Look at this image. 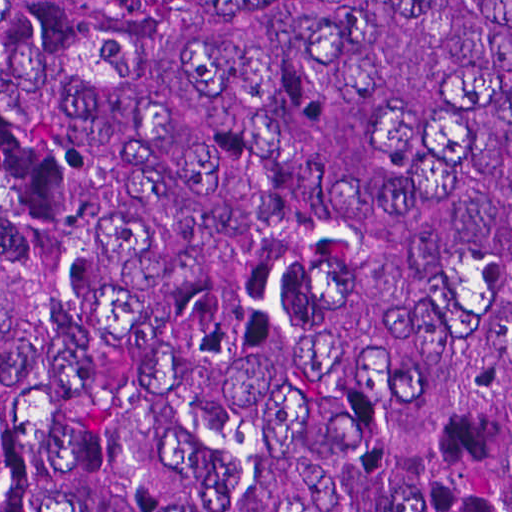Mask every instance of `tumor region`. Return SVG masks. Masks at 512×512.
<instances>
[{"label": "tumor region", "instance_id": "e687c5a6", "mask_svg": "<svg viewBox=\"0 0 512 512\" xmlns=\"http://www.w3.org/2000/svg\"><path fill=\"white\" fill-rule=\"evenodd\" d=\"M0 512H512V0H0Z\"/></svg>", "mask_w": 512, "mask_h": 512}]
</instances>
